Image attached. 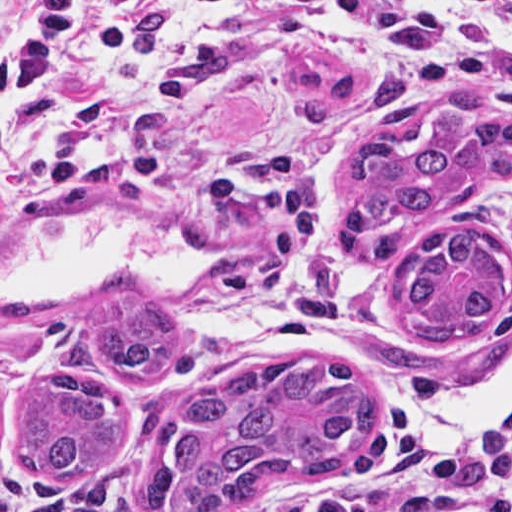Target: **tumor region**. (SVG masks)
<instances>
[{"label": "tumor region", "mask_w": 512, "mask_h": 512, "mask_svg": "<svg viewBox=\"0 0 512 512\" xmlns=\"http://www.w3.org/2000/svg\"><path fill=\"white\" fill-rule=\"evenodd\" d=\"M512 161V114L477 120L444 144L409 153L388 135L357 142L339 178L336 217L375 231L477 187ZM505 306V261L468 228L431 234L396 286L397 311L425 343L481 333ZM170 352V324L146 291H113L101 315L74 329L61 351L79 368L149 379ZM371 432L361 379L317 353L233 367L200 383L133 496L101 512H247L279 483H319L345 469ZM131 440L123 401L101 377L53 372L33 382L18 410L12 459L42 482L75 485L109 468Z\"/></svg>", "instance_id": "1"}]
</instances>
